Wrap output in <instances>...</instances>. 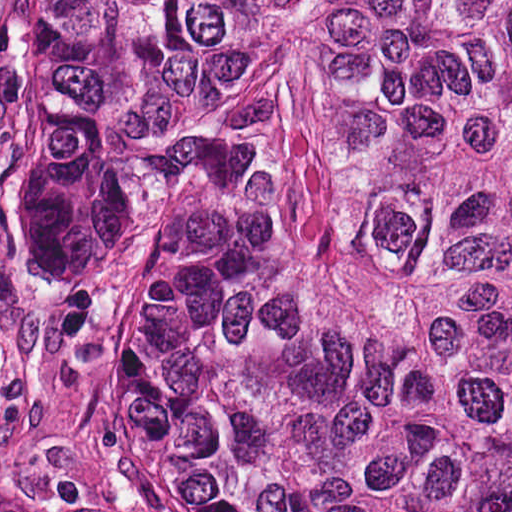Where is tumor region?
<instances>
[{
	"instance_id": "tumor-region-1",
	"label": "tumor region",
	"mask_w": 512,
	"mask_h": 512,
	"mask_svg": "<svg viewBox=\"0 0 512 512\" xmlns=\"http://www.w3.org/2000/svg\"><path fill=\"white\" fill-rule=\"evenodd\" d=\"M20 11L65 381L145 482L512 512V0Z\"/></svg>"
}]
</instances>
